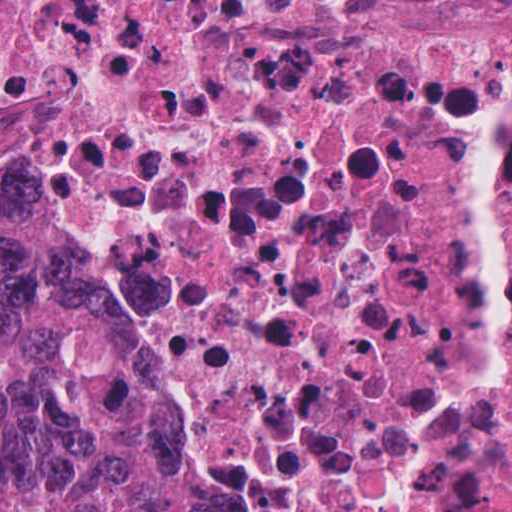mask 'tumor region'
Listing matches in <instances>:
<instances>
[{
    "label": "tumor region",
    "mask_w": 512,
    "mask_h": 512,
    "mask_svg": "<svg viewBox=\"0 0 512 512\" xmlns=\"http://www.w3.org/2000/svg\"><path fill=\"white\" fill-rule=\"evenodd\" d=\"M0 512H205L95 275L47 218L1 212Z\"/></svg>",
    "instance_id": "tumor-region-1"
}]
</instances>
